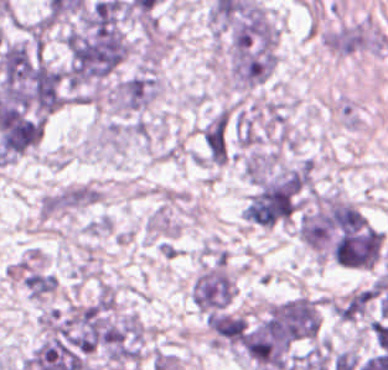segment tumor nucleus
<instances>
[{
	"label": "tumor nucleus",
	"mask_w": 388,
	"mask_h": 370,
	"mask_svg": "<svg viewBox=\"0 0 388 370\" xmlns=\"http://www.w3.org/2000/svg\"><path fill=\"white\" fill-rule=\"evenodd\" d=\"M233 292L228 258L216 254L192 278L189 299L197 312L207 315L226 308Z\"/></svg>",
	"instance_id": "obj_1"
},
{
	"label": "tumor nucleus",
	"mask_w": 388,
	"mask_h": 370,
	"mask_svg": "<svg viewBox=\"0 0 388 370\" xmlns=\"http://www.w3.org/2000/svg\"><path fill=\"white\" fill-rule=\"evenodd\" d=\"M154 74L141 71L117 84L110 90V106L118 113H134L144 110L156 97Z\"/></svg>",
	"instance_id": "obj_2"
},
{
	"label": "tumor nucleus",
	"mask_w": 388,
	"mask_h": 370,
	"mask_svg": "<svg viewBox=\"0 0 388 370\" xmlns=\"http://www.w3.org/2000/svg\"><path fill=\"white\" fill-rule=\"evenodd\" d=\"M321 44L340 54L378 52L379 38L367 23L355 22L325 32Z\"/></svg>",
	"instance_id": "obj_3"
}]
</instances>
